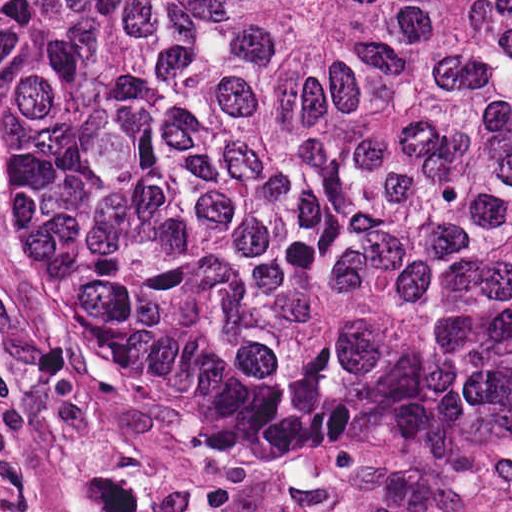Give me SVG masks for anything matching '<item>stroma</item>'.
<instances>
[{
    "mask_svg": "<svg viewBox=\"0 0 512 512\" xmlns=\"http://www.w3.org/2000/svg\"><path fill=\"white\" fill-rule=\"evenodd\" d=\"M0 512H512V457H280L144 392L0 172Z\"/></svg>",
    "mask_w": 512,
    "mask_h": 512,
    "instance_id": "obj_1",
    "label": "stroma"
}]
</instances>
